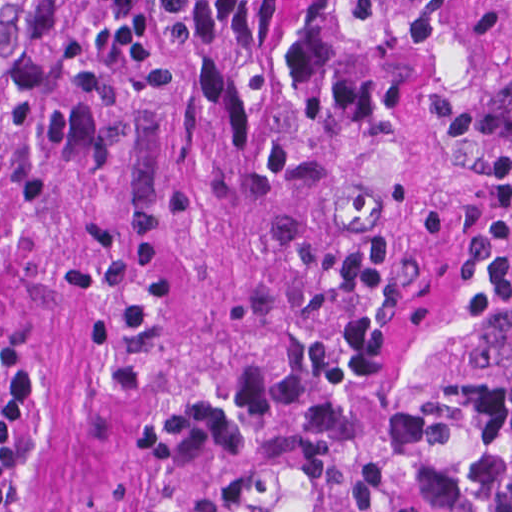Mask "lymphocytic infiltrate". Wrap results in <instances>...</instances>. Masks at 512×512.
<instances>
[{
    "label": "lymphocytic infiltrate",
    "instance_id": "1",
    "mask_svg": "<svg viewBox=\"0 0 512 512\" xmlns=\"http://www.w3.org/2000/svg\"><path fill=\"white\" fill-rule=\"evenodd\" d=\"M450 512H512V388L491 415L480 457Z\"/></svg>",
    "mask_w": 512,
    "mask_h": 512
}]
</instances>
